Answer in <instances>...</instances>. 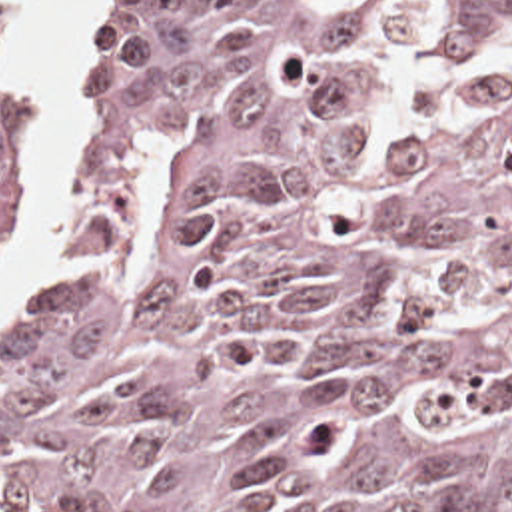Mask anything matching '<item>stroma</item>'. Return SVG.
<instances>
[{
    "mask_svg": "<svg viewBox=\"0 0 512 512\" xmlns=\"http://www.w3.org/2000/svg\"><path fill=\"white\" fill-rule=\"evenodd\" d=\"M149 2L151 0H127L123 18L115 26V30L107 36V40L99 52V60H97L87 84L83 86L81 94L73 102L61 104V100L49 80L47 60L41 52L39 38L29 22L27 0H0L1 12L7 20L15 48L19 52V56L23 58V62L27 64V68L31 70V74L35 76L39 94H41V198H43L45 180H47V174H49V168L53 162V140H51L49 126L55 122V118H59L67 112H71V116H73V206L63 212V234H61L57 246L43 252L31 264L27 280L17 296V302H19L21 294L43 272H47L49 268H53L57 262L63 260L67 248L71 246V242L75 238L79 208L89 190V128H91V120H93V112H95L97 104L109 90V54L115 48V44L121 40V36L143 18ZM39 208H41V204H39ZM13 256H15V250L0 260V284L5 280V276L11 268ZM9 320H7V324H9ZM7 324L3 326V330L7 328ZM3 330H1V334H3Z\"/></svg>",
    "mask_w": 512,
    "mask_h": 512,
    "instance_id": "35a3bbf8",
    "label": "stroma"
}]
</instances>
